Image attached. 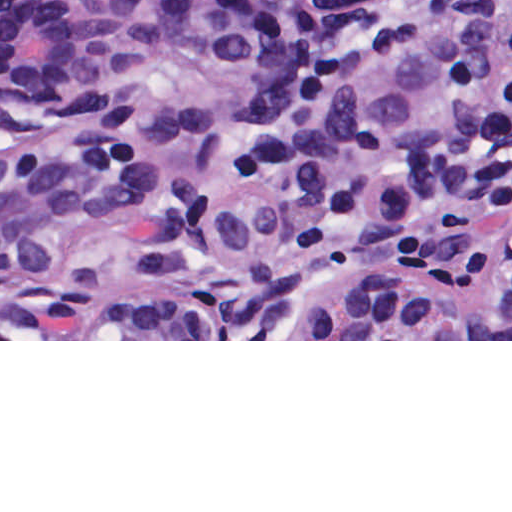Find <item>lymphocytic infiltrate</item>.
Masks as SVG:
<instances>
[{"instance_id": "lymphocytic-infiltrate-1", "label": "lymphocytic infiltrate", "mask_w": 512, "mask_h": 512, "mask_svg": "<svg viewBox=\"0 0 512 512\" xmlns=\"http://www.w3.org/2000/svg\"><path fill=\"white\" fill-rule=\"evenodd\" d=\"M496 69V112L503 217L512 236V0H466Z\"/></svg>"}]
</instances>
